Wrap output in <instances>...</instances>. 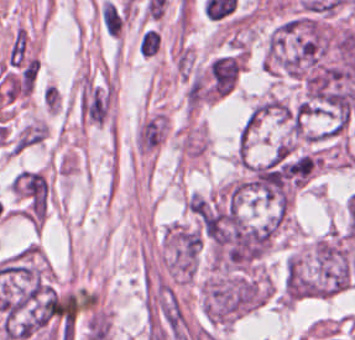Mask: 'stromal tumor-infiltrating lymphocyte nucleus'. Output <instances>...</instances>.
<instances>
[{"mask_svg": "<svg viewBox=\"0 0 355 340\" xmlns=\"http://www.w3.org/2000/svg\"><path fill=\"white\" fill-rule=\"evenodd\" d=\"M101 20L107 34L116 36L120 26V17L113 3L104 0L101 7Z\"/></svg>", "mask_w": 355, "mask_h": 340, "instance_id": "1", "label": "stromal tumor-infiltrating lymphocyte nucleus"}, {"mask_svg": "<svg viewBox=\"0 0 355 340\" xmlns=\"http://www.w3.org/2000/svg\"><path fill=\"white\" fill-rule=\"evenodd\" d=\"M114 7V11H115V15H116V20H117V24H118V28L119 31L121 30V28L123 27V23H124V12L121 11L118 7H116L113 4Z\"/></svg>", "mask_w": 355, "mask_h": 340, "instance_id": "2", "label": "stromal tumor-infiltrating lymphocyte nucleus"}]
</instances>
